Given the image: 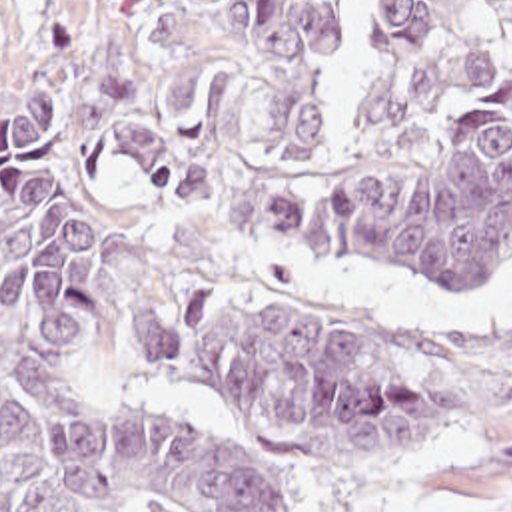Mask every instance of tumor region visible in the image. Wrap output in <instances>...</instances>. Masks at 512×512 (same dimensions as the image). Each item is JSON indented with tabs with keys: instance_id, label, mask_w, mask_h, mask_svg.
<instances>
[{
	"instance_id": "e687c5a6",
	"label": "tumor region",
	"mask_w": 512,
	"mask_h": 512,
	"mask_svg": "<svg viewBox=\"0 0 512 512\" xmlns=\"http://www.w3.org/2000/svg\"><path fill=\"white\" fill-rule=\"evenodd\" d=\"M128 164L180 204L375 264L457 280L512 256V0H140L108 72ZM66 86L0 110V512H292L240 446L186 418L80 422L58 394L98 324L100 222L36 154ZM463 340L359 332L252 282L184 288L150 376L246 416L292 466H363L477 420Z\"/></svg>"
}]
</instances>
